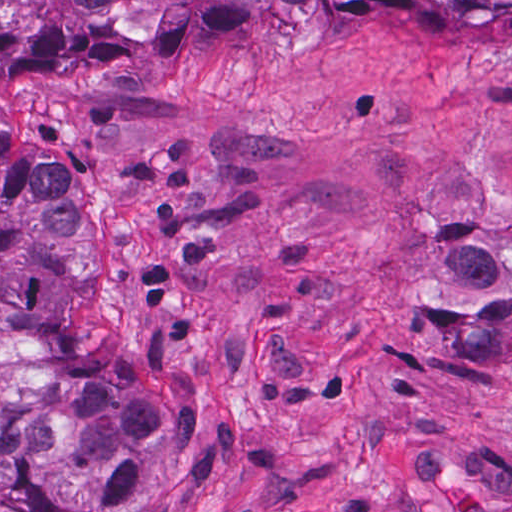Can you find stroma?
<instances>
[{
	"label": "stroma",
	"mask_w": 512,
	"mask_h": 512,
	"mask_svg": "<svg viewBox=\"0 0 512 512\" xmlns=\"http://www.w3.org/2000/svg\"><path fill=\"white\" fill-rule=\"evenodd\" d=\"M0 119L78 181L95 326L195 381L218 460L179 512H512V343L479 336L512 314V2L46 43Z\"/></svg>",
	"instance_id": "obj_1"
}]
</instances>
